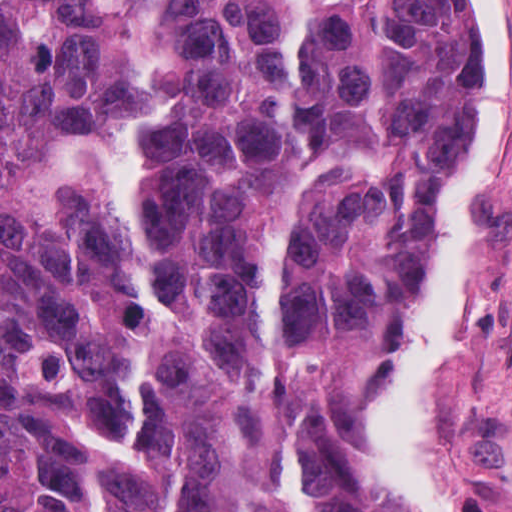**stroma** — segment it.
Wrapping results in <instances>:
<instances>
[{
  "mask_svg": "<svg viewBox=\"0 0 512 512\" xmlns=\"http://www.w3.org/2000/svg\"><path fill=\"white\" fill-rule=\"evenodd\" d=\"M465 2L475 30V0ZM498 52L505 83V155L498 185L490 286L462 340V432L455 492L468 512H484L476 485L512 504V0H498ZM463 195L431 233L395 333L368 363L347 421L346 456L357 468L358 439L372 396Z\"/></svg>",
  "mask_w": 512,
  "mask_h": 512,
  "instance_id": "stroma-1",
  "label": "stroma"
}]
</instances>
